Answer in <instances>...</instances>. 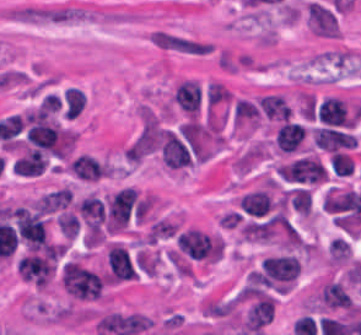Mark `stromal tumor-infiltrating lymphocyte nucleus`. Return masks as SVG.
<instances>
[{
    "mask_svg": "<svg viewBox=\"0 0 361 335\" xmlns=\"http://www.w3.org/2000/svg\"><path fill=\"white\" fill-rule=\"evenodd\" d=\"M84 106H85V93H84L83 89L81 88V98H80V109H81V112H82Z\"/></svg>",
    "mask_w": 361,
    "mask_h": 335,
    "instance_id": "stromal-tumor-infiltrating-lymphocyte-nucleus-1",
    "label": "stromal tumor-infiltrating lymphocyte nucleus"
}]
</instances>
